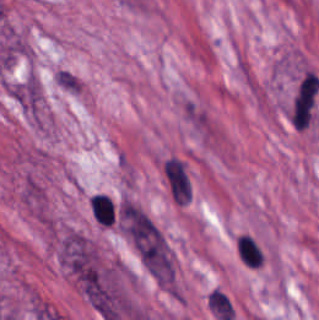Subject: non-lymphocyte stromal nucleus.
Listing matches in <instances>:
<instances>
[{
    "label": "non-lymphocyte stromal nucleus",
    "instance_id": "non-lymphocyte-stromal-nucleus-3",
    "mask_svg": "<svg viewBox=\"0 0 319 320\" xmlns=\"http://www.w3.org/2000/svg\"><path fill=\"white\" fill-rule=\"evenodd\" d=\"M207 301L210 305L213 315L221 320H231L233 318V309L228 297L219 289H212Z\"/></svg>",
    "mask_w": 319,
    "mask_h": 320
},
{
    "label": "non-lymphocyte stromal nucleus",
    "instance_id": "non-lymphocyte-stromal-nucleus-2",
    "mask_svg": "<svg viewBox=\"0 0 319 320\" xmlns=\"http://www.w3.org/2000/svg\"><path fill=\"white\" fill-rule=\"evenodd\" d=\"M158 167L169 202L185 207L189 205L192 184L186 160L176 153H169Z\"/></svg>",
    "mask_w": 319,
    "mask_h": 320
},
{
    "label": "non-lymphocyte stromal nucleus",
    "instance_id": "non-lymphocyte-stromal-nucleus-1",
    "mask_svg": "<svg viewBox=\"0 0 319 320\" xmlns=\"http://www.w3.org/2000/svg\"><path fill=\"white\" fill-rule=\"evenodd\" d=\"M60 262L83 290L93 289L97 277L95 250L91 242L78 234L61 238Z\"/></svg>",
    "mask_w": 319,
    "mask_h": 320
}]
</instances>
